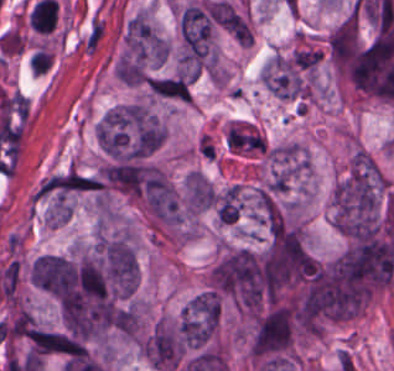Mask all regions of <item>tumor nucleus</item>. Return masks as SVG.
I'll return each instance as SVG.
<instances>
[{"label": "tumor nucleus", "instance_id": "1", "mask_svg": "<svg viewBox=\"0 0 394 371\" xmlns=\"http://www.w3.org/2000/svg\"><path fill=\"white\" fill-rule=\"evenodd\" d=\"M220 317L219 297L207 292L184 309L179 328L184 347L199 348L210 340Z\"/></svg>", "mask_w": 394, "mask_h": 371}, {"label": "tumor nucleus", "instance_id": "2", "mask_svg": "<svg viewBox=\"0 0 394 371\" xmlns=\"http://www.w3.org/2000/svg\"><path fill=\"white\" fill-rule=\"evenodd\" d=\"M102 263L111 287L119 296H129L137 287V260L123 240L101 246Z\"/></svg>", "mask_w": 394, "mask_h": 371}, {"label": "tumor nucleus", "instance_id": "3", "mask_svg": "<svg viewBox=\"0 0 394 371\" xmlns=\"http://www.w3.org/2000/svg\"><path fill=\"white\" fill-rule=\"evenodd\" d=\"M150 85L157 96L187 102L190 98V84L183 75L155 77L150 80Z\"/></svg>", "mask_w": 394, "mask_h": 371}, {"label": "tumor nucleus", "instance_id": "4", "mask_svg": "<svg viewBox=\"0 0 394 371\" xmlns=\"http://www.w3.org/2000/svg\"><path fill=\"white\" fill-rule=\"evenodd\" d=\"M215 199V190L203 175H189L188 203L192 211L210 208Z\"/></svg>", "mask_w": 394, "mask_h": 371}]
</instances>
